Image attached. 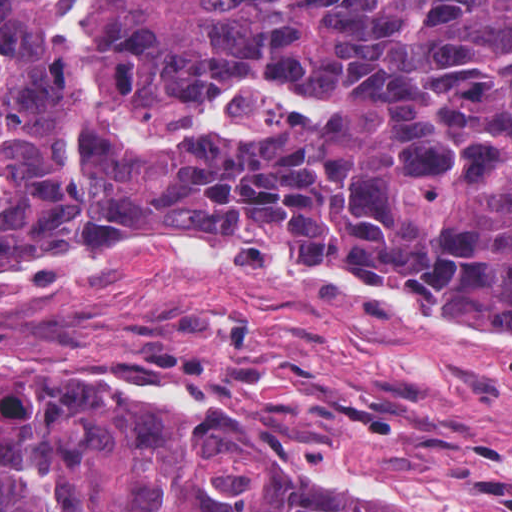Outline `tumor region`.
Returning a JSON list of instances; mask_svg holds the SVG:
<instances>
[{"mask_svg": "<svg viewBox=\"0 0 512 512\" xmlns=\"http://www.w3.org/2000/svg\"><path fill=\"white\" fill-rule=\"evenodd\" d=\"M0 0V268L139 238L329 263L512 330V0H93L90 83L190 119L242 84L240 142L82 134L46 27ZM103 352L0 371V512H410L324 494L242 439L103 392Z\"/></svg>", "mask_w": 512, "mask_h": 512, "instance_id": "tumor-region-1", "label": "tumor region"}]
</instances>
